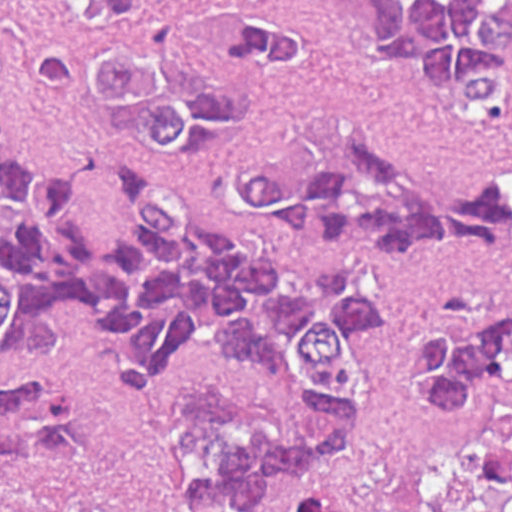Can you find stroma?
<instances>
[{
    "label": "stroma",
    "mask_w": 512,
    "mask_h": 512,
    "mask_svg": "<svg viewBox=\"0 0 512 512\" xmlns=\"http://www.w3.org/2000/svg\"><path fill=\"white\" fill-rule=\"evenodd\" d=\"M318 66L262 104L269 120L291 126L310 114H345L390 155L512 181V136L449 113L390 65L370 60L361 10L342 0H284ZM78 13L63 0H0V100L4 124L30 163L96 165L80 197L88 234L118 233L127 216L114 187L117 169L137 165L163 177L195 217L289 278L310 281L359 265L382 285V311L365 335L371 390L352 438L309 470L276 473L249 511L201 507L185 490L167 408L175 391L234 394L267 404L285 435L318 434V417L271 373L223 349L192 347L174 379L159 386L124 383L111 372L135 354L111 331L99 299L66 307L64 354H29L0 372H56L93 386L102 406L108 472L120 494L144 512H285L293 478L339 484L354 512H482L474 470L445 441L442 423L403 373V343L413 323L465 286L512 292V248H452L389 256L285 237L241 212L202 163L150 161L124 148L82 108L43 93L32 62L75 35Z\"/></svg>",
    "instance_id": "obj_1"
}]
</instances>
